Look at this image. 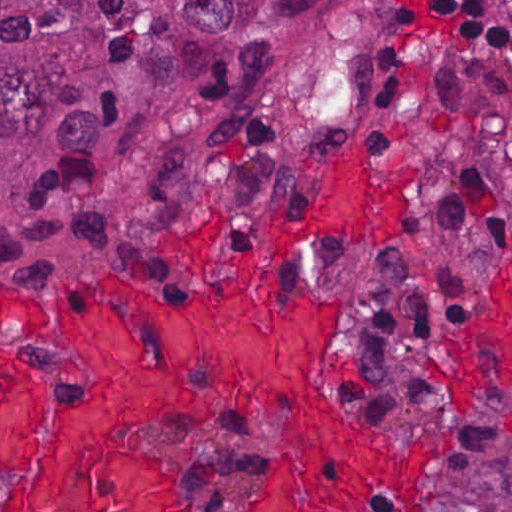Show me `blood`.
I'll return each mask as SVG.
<instances>
[{
	"label": "blood",
	"mask_w": 512,
	"mask_h": 512,
	"mask_svg": "<svg viewBox=\"0 0 512 512\" xmlns=\"http://www.w3.org/2000/svg\"><path fill=\"white\" fill-rule=\"evenodd\" d=\"M419 165H375L363 140L329 163L308 224H259L239 280L216 279L189 315L110 280L47 308L1 286L21 339L68 354L86 399L61 412L44 469L1 499V512H178L176 463L139 432L193 415L259 406L291 419L282 481L256 512H428L426 479L452 438L399 439L333 408L325 349L339 302L300 286L278 296L284 256L337 221L358 249L400 232ZM322 394L330 411L294 416Z\"/></svg>",
	"instance_id": "blood-1"
}]
</instances>
